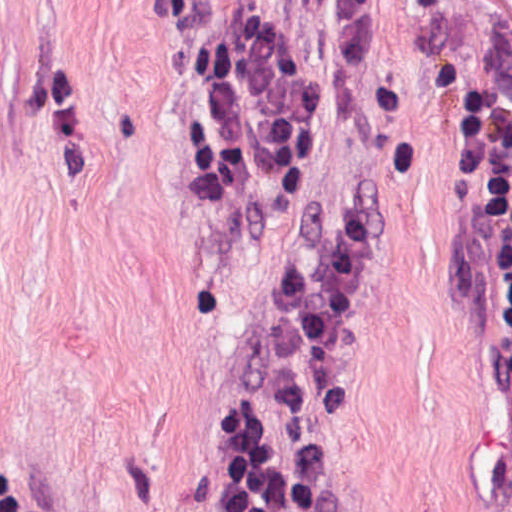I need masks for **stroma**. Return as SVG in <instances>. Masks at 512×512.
<instances>
[{
    "instance_id": "1",
    "label": "stroma",
    "mask_w": 512,
    "mask_h": 512,
    "mask_svg": "<svg viewBox=\"0 0 512 512\" xmlns=\"http://www.w3.org/2000/svg\"><path fill=\"white\" fill-rule=\"evenodd\" d=\"M171 0H0V512H231L207 439L321 217L386 259L328 435L342 512H512L499 330L450 250L512 0H372L291 207L219 232L186 176Z\"/></svg>"
}]
</instances>
